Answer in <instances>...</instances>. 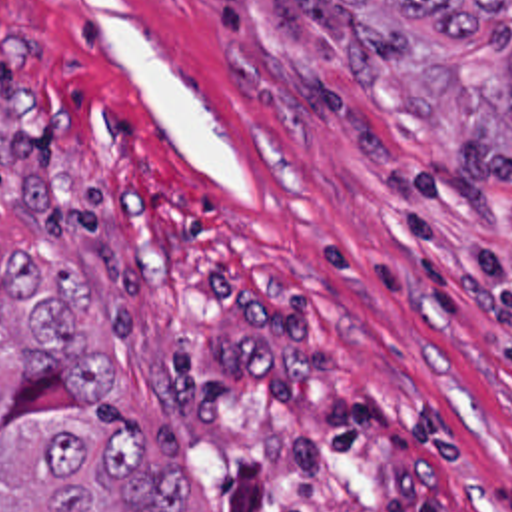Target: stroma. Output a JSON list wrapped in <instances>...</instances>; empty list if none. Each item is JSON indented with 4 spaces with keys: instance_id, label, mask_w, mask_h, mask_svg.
I'll use <instances>...</instances> for the list:
<instances>
[{
    "instance_id": "stroma-1",
    "label": "stroma",
    "mask_w": 512,
    "mask_h": 512,
    "mask_svg": "<svg viewBox=\"0 0 512 512\" xmlns=\"http://www.w3.org/2000/svg\"><path fill=\"white\" fill-rule=\"evenodd\" d=\"M313 9L0 0V265L85 273L189 512H512V153L395 109Z\"/></svg>"
}]
</instances>
